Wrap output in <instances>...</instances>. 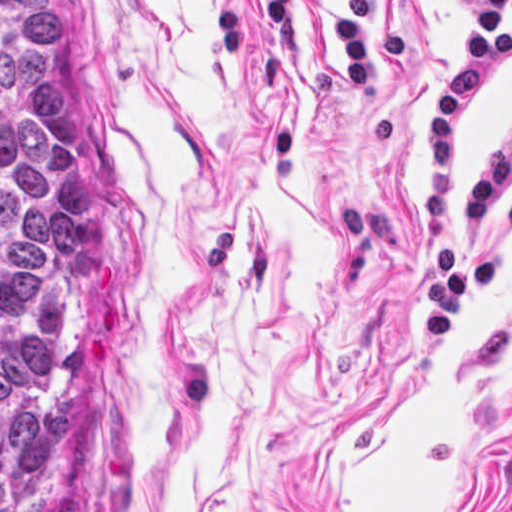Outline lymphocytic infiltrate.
<instances>
[{
	"label": "lymphocytic infiltrate",
	"instance_id": "lymphocytic-infiltrate-1",
	"mask_svg": "<svg viewBox=\"0 0 512 512\" xmlns=\"http://www.w3.org/2000/svg\"><path fill=\"white\" fill-rule=\"evenodd\" d=\"M329 1L354 99H366L376 91L374 37L380 62L392 74L414 63L411 29H388L380 24L378 0ZM456 2L459 54L433 94L426 150L423 270L430 290V329L439 343L446 339L463 299L498 278V259L483 246V227L493 198L507 175L512 176L510 119L493 147L472 168L448 216L463 162L466 119L512 62V0ZM258 4L282 59L311 51L296 0H258ZM504 223L512 231V204L504 211Z\"/></svg>",
	"mask_w": 512,
	"mask_h": 512
}]
</instances>
